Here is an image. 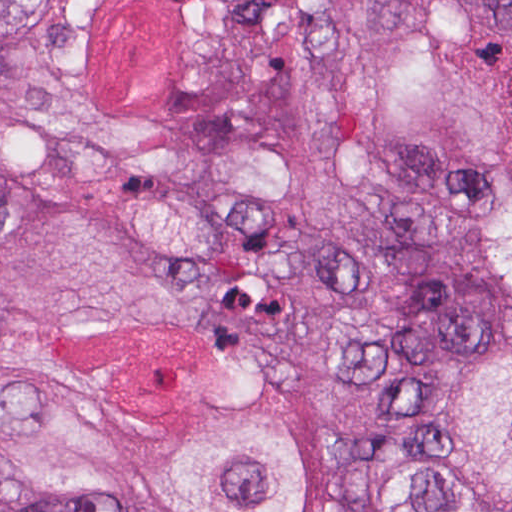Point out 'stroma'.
<instances>
[{
  "label": "stroma",
  "mask_w": 512,
  "mask_h": 512,
  "mask_svg": "<svg viewBox=\"0 0 512 512\" xmlns=\"http://www.w3.org/2000/svg\"><path fill=\"white\" fill-rule=\"evenodd\" d=\"M486 334H512V310H500L441 332L399 362L374 371V397L362 411L363 433L347 470V493L360 512H376L365 488V470L389 449L392 413L420 401L428 377L461 347Z\"/></svg>",
  "instance_id": "obj_1"
}]
</instances>
